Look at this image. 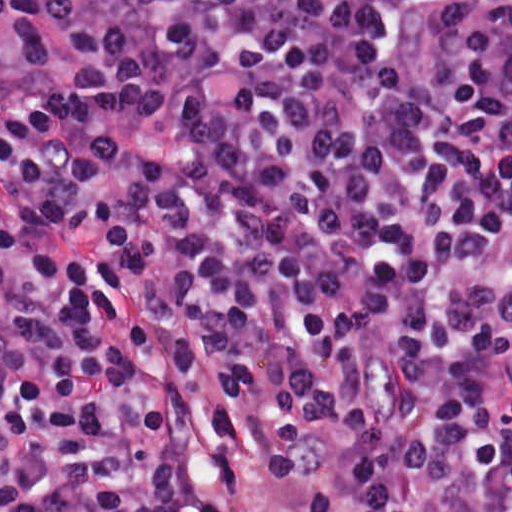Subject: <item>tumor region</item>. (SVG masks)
I'll return each instance as SVG.
<instances>
[{"label":"tumor region","instance_id":"1","mask_svg":"<svg viewBox=\"0 0 512 512\" xmlns=\"http://www.w3.org/2000/svg\"><path fill=\"white\" fill-rule=\"evenodd\" d=\"M492 290L512 316V268L495 266L492 273Z\"/></svg>","mask_w":512,"mask_h":512}]
</instances>
